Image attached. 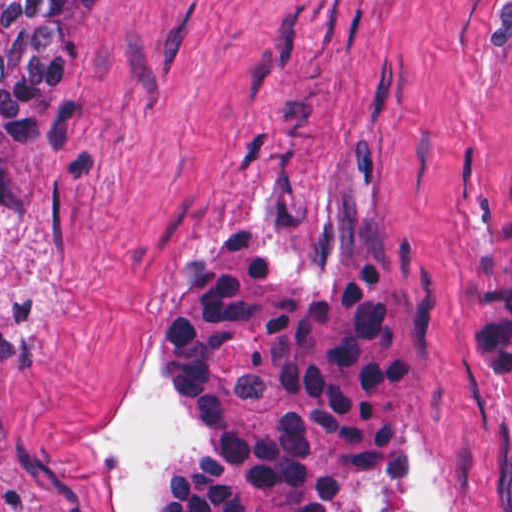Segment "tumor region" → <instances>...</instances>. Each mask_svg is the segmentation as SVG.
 <instances>
[{
  "label": "tumor region",
  "instance_id": "obj_1",
  "mask_svg": "<svg viewBox=\"0 0 512 512\" xmlns=\"http://www.w3.org/2000/svg\"><path fill=\"white\" fill-rule=\"evenodd\" d=\"M85 2L0 0V227ZM424 304L415 242L375 209L314 262L284 267L241 229L194 249L156 314L154 397L196 443L151 512H391ZM465 320L477 357L512 384V194Z\"/></svg>",
  "mask_w": 512,
  "mask_h": 512
}]
</instances>
